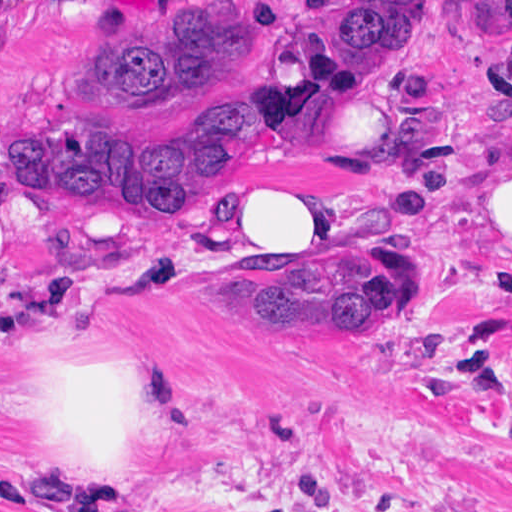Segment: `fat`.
<instances>
[{
    "label": "fat",
    "mask_w": 512,
    "mask_h": 512,
    "mask_svg": "<svg viewBox=\"0 0 512 512\" xmlns=\"http://www.w3.org/2000/svg\"><path fill=\"white\" fill-rule=\"evenodd\" d=\"M481 210L512 225V150L504 149L481 172ZM212 216L237 251L296 267L337 258L336 217L315 191L286 178L255 172L238 197ZM504 228L512 235V227ZM50 385L75 455L113 494L94 512L145 506L140 467L127 450L125 386L116 375L84 368Z\"/></svg>",
    "instance_id": "fat-1"
}]
</instances>
